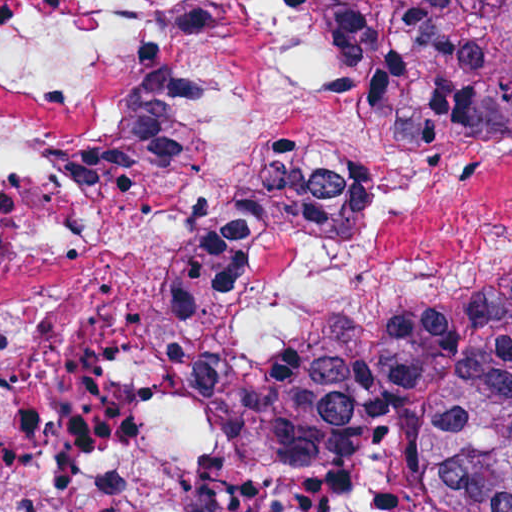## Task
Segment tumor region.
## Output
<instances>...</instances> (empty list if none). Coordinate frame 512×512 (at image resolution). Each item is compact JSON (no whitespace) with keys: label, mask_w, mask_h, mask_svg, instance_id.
Wrapping results in <instances>:
<instances>
[{"label":"tumor region","mask_w":512,"mask_h":512,"mask_svg":"<svg viewBox=\"0 0 512 512\" xmlns=\"http://www.w3.org/2000/svg\"><path fill=\"white\" fill-rule=\"evenodd\" d=\"M326 1L346 62L404 145L512 133V1H407L395 37ZM198 422L239 466L318 475L387 435L418 445V512H512V279L207 368ZM193 512H238L203 502Z\"/></svg>","instance_id":"tumor-region-1"}]
</instances>
